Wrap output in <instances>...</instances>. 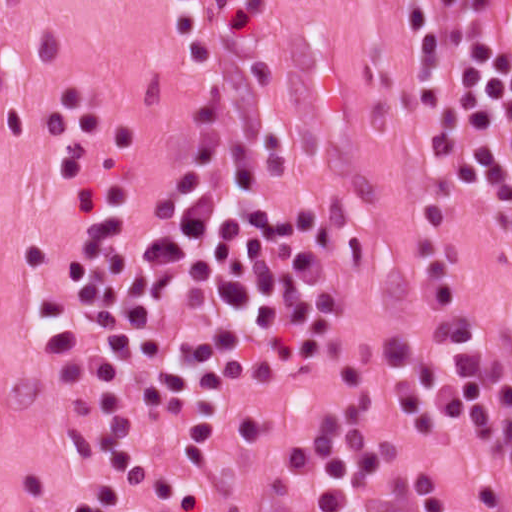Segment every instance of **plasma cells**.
Masks as SVG:
<instances>
[{"label":"plasma cells","mask_w":512,"mask_h":512,"mask_svg":"<svg viewBox=\"0 0 512 512\" xmlns=\"http://www.w3.org/2000/svg\"><path fill=\"white\" fill-rule=\"evenodd\" d=\"M404 2L449 198L512 214V80L487 64L484 0ZM173 37L188 117L90 251V334L117 415L70 429L72 453L100 476L63 512H136L144 492L171 500L179 479L142 451L141 427L194 438L242 421L340 287L336 217L313 186L273 179L240 0H178ZM392 356L420 434L485 452L502 478L494 512H512V365L441 234L399 302ZM373 415L369 402L346 404L280 452L307 507L458 512L433 482L380 473L389 457L367 434Z\"/></svg>","instance_id":"plasma-cells-1"}]
</instances>
